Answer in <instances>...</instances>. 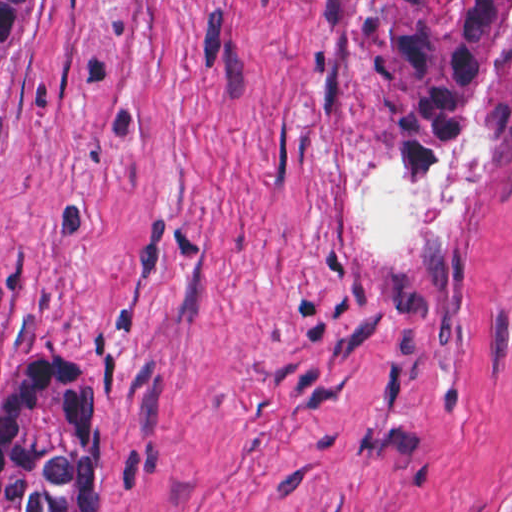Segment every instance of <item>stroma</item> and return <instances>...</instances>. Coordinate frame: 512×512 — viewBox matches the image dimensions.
Listing matches in <instances>:
<instances>
[{
    "label": "stroma",
    "instance_id": "stroma-1",
    "mask_svg": "<svg viewBox=\"0 0 512 512\" xmlns=\"http://www.w3.org/2000/svg\"><path fill=\"white\" fill-rule=\"evenodd\" d=\"M0 1V388L102 376L86 512H512V109L430 175L314 89L330 1L512 0Z\"/></svg>",
    "mask_w": 512,
    "mask_h": 512
}]
</instances>
